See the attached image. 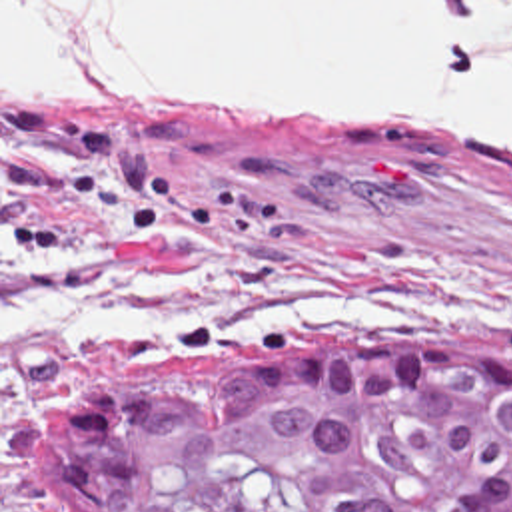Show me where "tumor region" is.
<instances>
[{
    "mask_svg": "<svg viewBox=\"0 0 512 512\" xmlns=\"http://www.w3.org/2000/svg\"><path fill=\"white\" fill-rule=\"evenodd\" d=\"M48 512H512V371L413 337L142 363L36 429Z\"/></svg>",
    "mask_w": 512,
    "mask_h": 512,
    "instance_id": "tumor-region-1",
    "label": "tumor region"
}]
</instances>
